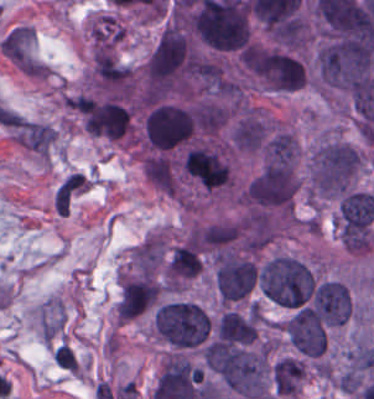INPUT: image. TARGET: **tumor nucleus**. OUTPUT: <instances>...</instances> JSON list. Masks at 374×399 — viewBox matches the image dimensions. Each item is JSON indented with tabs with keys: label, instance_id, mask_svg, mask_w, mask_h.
<instances>
[{
	"label": "tumor nucleus",
	"instance_id": "tumor-nucleus-7",
	"mask_svg": "<svg viewBox=\"0 0 374 399\" xmlns=\"http://www.w3.org/2000/svg\"><path fill=\"white\" fill-rule=\"evenodd\" d=\"M305 377L304 360L292 355L276 359L271 366L270 382L277 399L296 396L302 389Z\"/></svg>",
	"mask_w": 374,
	"mask_h": 399
},
{
	"label": "tumor nucleus",
	"instance_id": "tumor-nucleus-2",
	"mask_svg": "<svg viewBox=\"0 0 374 399\" xmlns=\"http://www.w3.org/2000/svg\"><path fill=\"white\" fill-rule=\"evenodd\" d=\"M152 330L172 349H195L211 333L206 311L193 301L171 298L159 303L151 314Z\"/></svg>",
	"mask_w": 374,
	"mask_h": 399
},
{
	"label": "tumor nucleus",
	"instance_id": "tumor-nucleus-5",
	"mask_svg": "<svg viewBox=\"0 0 374 399\" xmlns=\"http://www.w3.org/2000/svg\"><path fill=\"white\" fill-rule=\"evenodd\" d=\"M298 159V141L282 128L270 130L262 143L261 163L264 172H294Z\"/></svg>",
	"mask_w": 374,
	"mask_h": 399
},
{
	"label": "tumor nucleus",
	"instance_id": "tumor-nucleus-3",
	"mask_svg": "<svg viewBox=\"0 0 374 399\" xmlns=\"http://www.w3.org/2000/svg\"><path fill=\"white\" fill-rule=\"evenodd\" d=\"M196 116L182 102L157 101L142 118L141 141L151 153L175 151L192 140Z\"/></svg>",
	"mask_w": 374,
	"mask_h": 399
},
{
	"label": "tumor nucleus",
	"instance_id": "tumor-nucleus-4",
	"mask_svg": "<svg viewBox=\"0 0 374 399\" xmlns=\"http://www.w3.org/2000/svg\"><path fill=\"white\" fill-rule=\"evenodd\" d=\"M297 186L291 172L259 168L244 184L241 200L256 213H291Z\"/></svg>",
	"mask_w": 374,
	"mask_h": 399
},
{
	"label": "tumor nucleus",
	"instance_id": "tumor-nucleus-6",
	"mask_svg": "<svg viewBox=\"0 0 374 399\" xmlns=\"http://www.w3.org/2000/svg\"><path fill=\"white\" fill-rule=\"evenodd\" d=\"M203 257L193 241H184L170 252L166 277L173 287H183L198 277Z\"/></svg>",
	"mask_w": 374,
	"mask_h": 399
},
{
	"label": "tumor nucleus",
	"instance_id": "tumor-nucleus-1",
	"mask_svg": "<svg viewBox=\"0 0 374 399\" xmlns=\"http://www.w3.org/2000/svg\"><path fill=\"white\" fill-rule=\"evenodd\" d=\"M365 163L364 151L337 137H323L307 161V194L313 201L338 198L352 188Z\"/></svg>",
	"mask_w": 374,
	"mask_h": 399
}]
</instances>
